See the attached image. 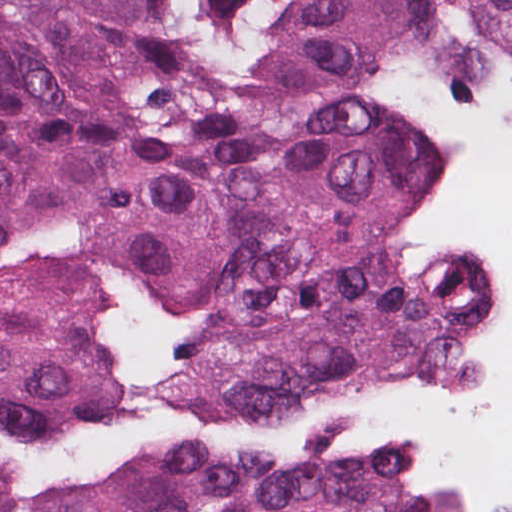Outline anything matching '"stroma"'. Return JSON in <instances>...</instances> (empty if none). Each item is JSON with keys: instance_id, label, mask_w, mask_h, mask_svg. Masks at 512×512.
<instances>
[{"instance_id": "stroma-1", "label": "stroma", "mask_w": 512, "mask_h": 512, "mask_svg": "<svg viewBox=\"0 0 512 512\" xmlns=\"http://www.w3.org/2000/svg\"><path fill=\"white\" fill-rule=\"evenodd\" d=\"M229 74L269 97L393 129L434 148L452 172L473 160L500 115L512 111V68L481 45L462 8L414 24L364 68L294 51L300 0H202ZM497 329L512 320V278L489 257ZM503 354L497 334L494 400ZM423 512H509L482 472L440 476Z\"/></svg>"}]
</instances>
